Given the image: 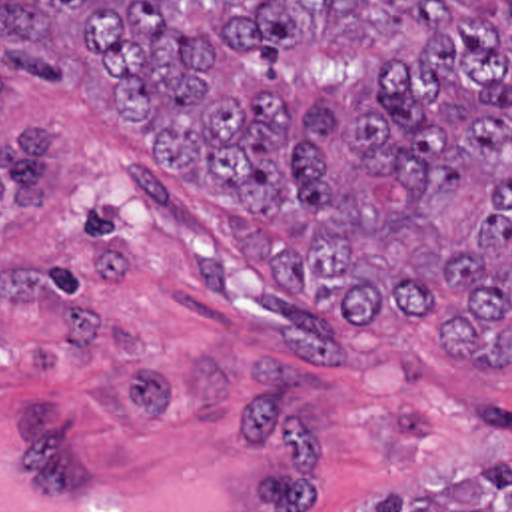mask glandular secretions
Wrapping results in <instances>:
<instances>
[{"mask_svg":"<svg viewBox=\"0 0 512 512\" xmlns=\"http://www.w3.org/2000/svg\"><path fill=\"white\" fill-rule=\"evenodd\" d=\"M11 424L0 418V512H235L231 462L209 454H175L121 488L69 478L17 480L9 464Z\"/></svg>","mask_w":512,"mask_h":512,"instance_id":"glandular-secretions-1","label":"glandular secretions"}]
</instances>
